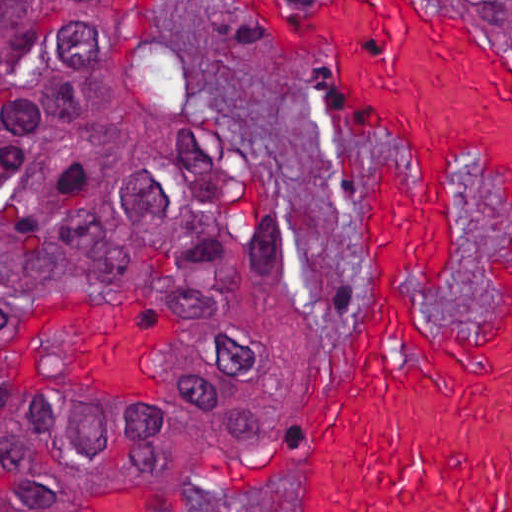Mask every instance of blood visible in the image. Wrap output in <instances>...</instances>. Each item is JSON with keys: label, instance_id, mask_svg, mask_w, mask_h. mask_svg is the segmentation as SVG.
<instances>
[{"label": "blood", "instance_id": "1", "mask_svg": "<svg viewBox=\"0 0 512 512\" xmlns=\"http://www.w3.org/2000/svg\"><path fill=\"white\" fill-rule=\"evenodd\" d=\"M220 2L326 55L420 179L379 173L366 197V314L308 512H512V64L428 1Z\"/></svg>", "mask_w": 512, "mask_h": 512}]
</instances>
